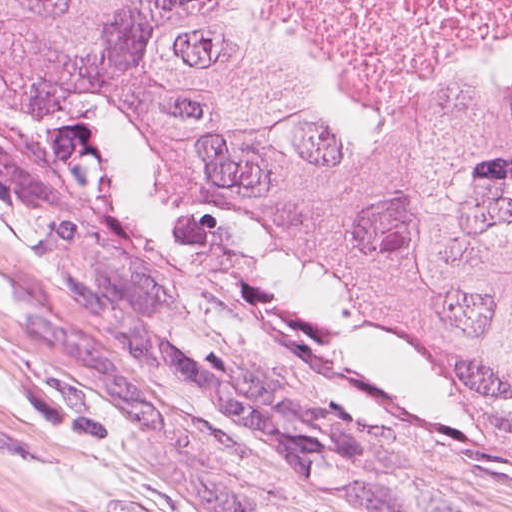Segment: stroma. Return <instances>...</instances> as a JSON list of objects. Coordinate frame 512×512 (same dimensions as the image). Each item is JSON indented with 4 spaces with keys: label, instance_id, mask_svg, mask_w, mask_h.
Masks as SVG:
<instances>
[{
    "label": "stroma",
    "instance_id": "obj_1",
    "mask_svg": "<svg viewBox=\"0 0 512 512\" xmlns=\"http://www.w3.org/2000/svg\"><path fill=\"white\" fill-rule=\"evenodd\" d=\"M222 2L296 80L385 82ZM0 512H512V410L152 169L105 103L0 89Z\"/></svg>",
    "mask_w": 512,
    "mask_h": 512
}]
</instances>
